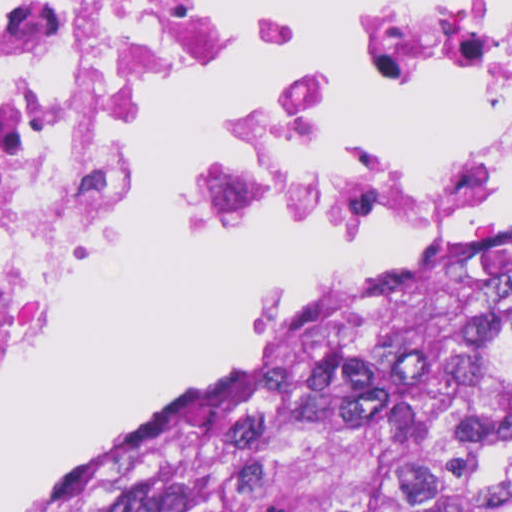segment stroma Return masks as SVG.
<instances>
[{
	"label": "stroma",
	"mask_w": 512,
	"mask_h": 512,
	"mask_svg": "<svg viewBox=\"0 0 512 512\" xmlns=\"http://www.w3.org/2000/svg\"><path fill=\"white\" fill-rule=\"evenodd\" d=\"M275 10L305 20L317 40V67L266 120L297 106L315 88L328 65L335 42L331 19L315 3L238 0L220 10L210 45L240 31L256 14ZM143 143L125 165V174ZM511 179L512 166L494 179L483 199L465 217L449 223L447 219L440 246L313 305L277 310L244 330L191 388L171 399L153 418L86 466L55 496L93 482L181 433L218 420L250 387L328 341L360 315L438 270L478 237L512 221V192L502 188ZM277 227L280 226H251L232 231L266 232ZM78 282L65 298L59 313L72 297Z\"/></svg>",
	"instance_id": "35a3bbf8"
}]
</instances>
